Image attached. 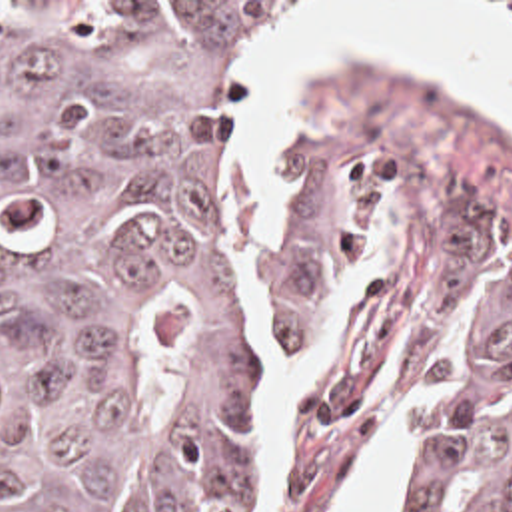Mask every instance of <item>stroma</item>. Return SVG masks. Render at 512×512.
<instances>
[{
    "instance_id": "obj_1",
    "label": "stroma",
    "mask_w": 512,
    "mask_h": 512,
    "mask_svg": "<svg viewBox=\"0 0 512 512\" xmlns=\"http://www.w3.org/2000/svg\"><path fill=\"white\" fill-rule=\"evenodd\" d=\"M0 2H299V22L249 94L239 146V278L249 337L275 409V501L267 512H341L413 391L411 443L389 512H405L443 409L457 351V236L512 258V126L451 86L361 60L303 72L277 144L279 196L251 232V106L307 24L315 2L512 0H0ZM367 254V285L345 313L317 379L291 401L279 433L273 357L333 337V305ZM359 266L355 268L357 276ZM359 281V278H357ZM347 305V287L343 291Z\"/></svg>"
}]
</instances>
